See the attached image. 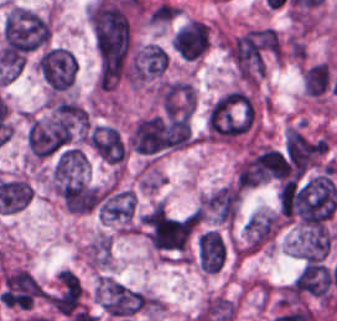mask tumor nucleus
I'll use <instances>...</instances> for the list:
<instances>
[{
    "label": "tumor nucleus",
    "instance_id": "2f306a5c",
    "mask_svg": "<svg viewBox=\"0 0 337 321\" xmlns=\"http://www.w3.org/2000/svg\"><path fill=\"white\" fill-rule=\"evenodd\" d=\"M96 88L110 92L133 84L131 25L128 19L93 24Z\"/></svg>",
    "mask_w": 337,
    "mask_h": 321
},
{
    "label": "tumor nucleus",
    "instance_id": "8643909e",
    "mask_svg": "<svg viewBox=\"0 0 337 321\" xmlns=\"http://www.w3.org/2000/svg\"><path fill=\"white\" fill-rule=\"evenodd\" d=\"M48 176L52 190L67 210L84 214L98 205V188L84 149L62 148Z\"/></svg>",
    "mask_w": 337,
    "mask_h": 321
},
{
    "label": "tumor nucleus",
    "instance_id": "5ab6c2c4",
    "mask_svg": "<svg viewBox=\"0 0 337 321\" xmlns=\"http://www.w3.org/2000/svg\"><path fill=\"white\" fill-rule=\"evenodd\" d=\"M258 101L244 87H231L213 102L207 117V141L234 143L255 130Z\"/></svg>",
    "mask_w": 337,
    "mask_h": 321
},
{
    "label": "tumor nucleus",
    "instance_id": "2cbd58db",
    "mask_svg": "<svg viewBox=\"0 0 337 321\" xmlns=\"http://www.w3.org/2000/svg\"><path fill=\"white\" fill-rule=\"evenodd\" d=\"M197 223L198 211L151 207L141 220V228L151 251L185 260Z\"/></svg>",
    "mask_w": 337,
    "mask_h": 321
},
{
    "label": "tumor nucleus",
    "instance_id": "3d1891a8",
    "mask_svg": "<svg viewBox=\"0 0 337 321\" xmlns=\"http://www.w3.org/2000/svg\"><path fill=\"white\" fill-rule=\"evenodd\" d=\"M279 38L274 30L251 27L229 38V62L241 84H259L278 55Z\"/></svg>",
    "mask_w": 337,
    "mask_h": 321
},
{
    "label": "tumor nucleus",
    "instance_id": "2083b535",
    "mask_svg": "<svg viewBox=\"0 0 337 321\" xmlns=\"http://www.w3.org/2000/svg\"><path fill=\"white\" fill-rule=\"evenodd\" d=\"M83 121L82 107L67 100L32 114L27 129L30 154L42 157L62 146L83 126Z\"/></svg>",
    "mask_w": 337,
    "mask_h": 321
},
{
    "label": "tumor nucleus",
    "instance_id": "8087334f",
    "mask_svg": "<svg viewBox=\"0 0 337 321\" xmlns=\"http://www.w3.org/2000/svg\"><path fill=\"white\" fill-rule=\"evenodd\" d=\"M97 302L105 314L115 321L141 315L154 308L150 295L113 277H99Z\"/></svg>",
    "mask_w": 337,
    "mask_h": 321
},
{
    "label": "tumor nucleus",
    "instance_id": "c2bd9aea",
    "mask_svg": "<svg viewBox=\"0 0 337 321\" xmlns=\"http://www.w3.org/2000/svg\"><path fill=\"white\" fill-rule=\"evenodd\" d=\"M35 69L52 95H63L74 84L77 59L64 48L51 45L40 51Z\"/></svg>",
    "mask_w": 337,
    "mask_h": 321
},
{
    "label": "tumor nucleus",
    "instance_id": "feef74b5",
    "mask_svg": "<svg viewBox=\"0 0 337 321\" xmlns=\"http://www.w3.org/2000/svg\"><path fill=\"white\" fill-rule=\"evenodd\" d=\"M97 211L102 221L120 230L134 231L136 196L133 190L110 184L99 189Z\"/></svg>",
    "mask_w": 337,
    "mask_h": 321
},
{
    "label": "tumor nucleus",
    "instance_id": "3e47fb67",
    "mask_svg": "<svg viewBox=\"0 0 337 321\" xmlns=\"http://www.w3.org/2000/svg\"><path fill=\"white\" fill-rule=\"evenodd\" d=\"M89 142L94 154L112 167H122L126 158L124 137L111 125L93 123Z\"/></svg>",
    "mask_w": 337,
    "mask_h": 321
},
{
    "label": "tumor nucleus",
    "instance_id": "f7901128",
    "mask_svg": "<svg viewBox=\"0 0 337 321\" xmlns=\"http://www.w3.org/2000/svg\"><path fill=\"white\" fill-rule=\"evenodd\" d=\"M167 58L156 43L135 48L129 58L130 76L134 81H154L166 70Z\"/></svg>",
    "mask_w": 337,
    "mask_h": 321
},
{
    "label": "tumor nucleus",
    "instance_id": "268c6acd",
    "mask_svg": "<svg viewBox=\"0 0 337 321\" xmlns=\"http://www.w3.org/2000/svg\"><path fill=\"white\" fill-rule=\"evenodd\" d=\"M200 208L220 224H230L236 215L239 194L232 184H225L198 199Z\"/></svg>",
    "mask_w": 337,
    "mask_h": 321
},
{
    "label": "tumor nucleus",
    "instance_id": "1edb0cf7",
    "mask_svg": "<svg viewBox=\"0 0 337 321\" xmlns=\"http://www.w3.org/2000/svg\"><path fill=\"white\" fill-rule=\"evenodd\" d=\"M290 291L327 301V267L319 262L305 261L293 279Z\"/></svg>",
    "mask_w": 337,
    "mask_h": 321
},
{
    "label": "tumor nucleus",
    "instance_id": "962dda3e",
    "mask_svg": "<svg viewBox=\"0 0 337 321\" xmlns=\"http://www.w3.org/2000/svg\"><path fill=\"white\" fill-rule=\"evenodd\" d=\"M175 50L185 59H195L207 50L208 25L190 19L174 35Z\"/></svg>",
    "mask_w": 337,
    "mask_h": 321
},
{
    "label": "tumor nucleus",
    "instance_id": "80c4ae96",
    "mask_svg": "<svg viewBox=\"0 0 337 321\" xmlns=\"http://www.w3.org/2000/svg\"><path fill=\"white\" fill-rule=\"evenodd\" d=\"M81 294L78 277L62 269L56 275L50 302L58 313L69 314L79 305Z\"/></svg>",
    "mask_w": 337,
    "mask_h": 321
},
{
    "label": "tumor nucleus",
    "instance_id": "3d7bf9ca",
    "mask_svg": "<svg viewBox=\"0 0 337 321\" xmlns=\"http://www.w3.org/2000/svg\"><path fill=\"white\" fill-rule=\"evenodd\" d=\"M332 241L330 231L318 227L296 235L293 255L304 260L321 261Z\"/></svg>",
    "mask_w": 337,
    "mask_h": 321
},
{
    "label": "tumor nucleus",
    "instance_id": "b15415a9",
    "mask_svg": "<svg viewBox=\"0 0 337 321\" xmlns=\"http://www.w3.org/2000/svg\"><path fill=\"white\" fill-rule=\"evenodd\" d=\"M199 266L206 272H217L226 257L223 241L214 230H207L197 239Z\"/></svg>",
    "mask_w": 337,
    "mask_h": 321
},
{
    "label": "tumor nucleus",
    "instance_id": "c6f8f39e",
    "mask_svg": "<svg viewBox=\"0 0 337 321\" xmlns=\"http://www.w3.org/2000/svg\"><path fill=\"white\" fill-rule=\"evenodd\" d=\"M301 87L310 97L323 98L328 95L331 90V70L328 64L320 60L303 68Z\"/></svg>",
    "mask_w": 337,
    "mask_h": 321
}]
</instances>
